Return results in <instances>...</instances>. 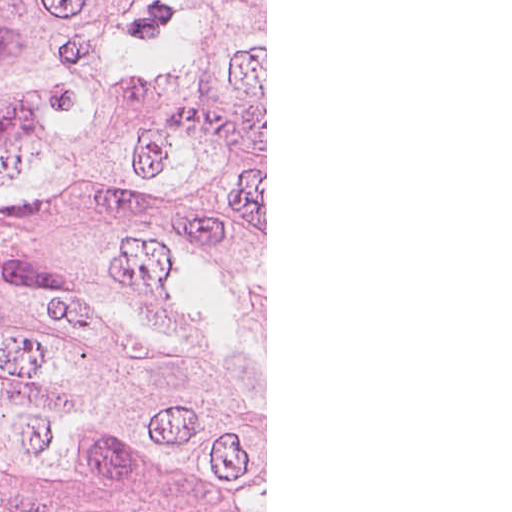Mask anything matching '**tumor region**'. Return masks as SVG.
<instances>
[{
	"label": "tumor region",
	"mask_w": 512,
	"mask_h": 512,
	"mask_svg": "<svg viewBox=\"0 0 512 512\" xmlns=\"http://www.w3.org/2000/svg\"><path fill=\"white\" fill-rule=\"evenodd\" d=\"M161 0H0V512H52Z\"/></svg>",
	"instance_id": "obj_1"
}]
</instances>
